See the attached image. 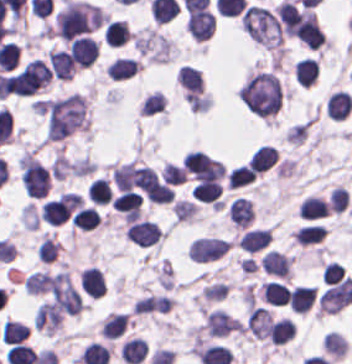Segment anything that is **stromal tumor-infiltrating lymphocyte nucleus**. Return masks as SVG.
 Wrapping results in <instances>:
<instances>
[{
    "mask_svg": "<svg viewBox=\"0 0 352 364\" xmlns=\"http://www.w3.org/2000/svg\"><path fill=\"white\" fill-rule=\"evenodd\" d=\"M182 163L186 172L197 180L219 179L224 173L223 164L198 150L184 155Z\"/></svg>",
    "mask_w": 352,
    "mask_h": 364,
    "instance_id": "1",
    "label": "stromal tumor-infiltrating lymphocyte nucleus"
},
{
    "mask_svg": "<svg viewBox=\"0 0 352 364\" xmlns=\"http://www.w3.org/2000/svg\"><path fill=\"white\" fill-rule=\"evenodd\" d=\"M229 244L223 238L197 237L187 248V255L193 262H209L218 259Z\"/></svg>",
    "mask_w": 352,
    "mask_h": 364,
    "instance_id": "2",
    "label": "stromal tumor-infiltrating lymphocyte nucleus"
},
{
    "mask_svg": "<svg viewBox=\"0 0 352 364\" xmlns=\"http://www.w3.org/2000/svg\"><path fill=\"white\" fill-rule=\"evenodd\" d=\"M124 233L130 242L141 247L152 246L162 235V231L155 221L137 218L129 224Z\"/></svg>",
    "mask_w": 352,
    "mask_h": 364,
    "instance_id": "3",
    "label": "stromal tumor-infiltrating lymphocyte nucleus"
},
{
    "mask_svg": "<svg viewBox=\"0 0 352 364\" xmlns=\"http://www.w3.org/2000/svg\"><path fill=\"white\" fill-rule=\"evenodd\" d=\"M68 49L77 67H89L98 55L96 40L83 35L71 40Z\"/></svg>",
    "mask_w": 352,
    "mask_h": 364,
    "instance_id": "4",
    "label": "stromal tumor-infiltrating lymphocyte nucleus"
},
{
    "mask_svg": "<svg viewBox=\"0 0 352 364\" xmlns=\"http://www.w3.org/2000/svg\"><path fill=\"white\" fill-rule=\"evenodd\" d=\"M185 26L191 36L204 40L211 36L214 28V14L211 10L201 9L187 16Z\"/></svg>",
    "mask_w": 352,
    "mask_h": 364,
    "instance_id": "5",
    "label": "stromal tumor-infiltrating lymphocyte nucleus"
},
{
    "mask_svg": "<svg viewBox=\"0 0 352 364\" xmlns=\"http://www.w3.org/2000/svg\"><path fill=\"white\" fill-rule=\"evenodd\" d=\"M79 281L84 293L89 296L96 299L104 295L105 278L99 267L92 264L82 269L79 274Z\"/></svg>",
    "mask_w": 352,
    "mask_h": 364,
    "instance_id": "6",
    "label": "stromal tumor-infiltrating lymphocyte nucleus"
},
{
    "mask_svg": "<svg viewBox=\"0 0 352 364\" xmlns=\"http://www.w3.org/2000/svg\"><path fill=\"white\" fill-rule=\"evenodd\" d=\"M259 261L265 274L287 277L291 259L286 254L267 249Z\"/></svg>",
    "mask_w": 352,
    "mask_h": 364,
    "instance_id": "7",
    "label": "stromal tumor-infiltrating lymphocyte nucleus"
},
{
    "mask_svg": "<svg viewBox=\"0 0 352 364\" xmlns=\"http://www.w3.org/2000/svg\"><path fill=\"white\" fill-rule=\"evenodd\" d=\"M185 97H193L203 91V80L197 68L181 66L176 77Z\"/></svg>",
    "mask_w": 352,
    "mask_h": 364,
    "instance_id": "8",
    "label": "stromal tumor-infiltrating lymphocyte nucleus"
},
{
    "mask_svg": "<svg viewBox=\"0 0 352 364\" xmlns=\"http://www.w3.org/2000/svg\"><path fill=\"white\" fill-rule=\"evenodd\" d=\"M48 67L52 76L61 79H70L75 67L64 50H49L47 52Z\"/></svg>",
    "mask_w": 352,
    "mask_h": 364,
    "instance_id": "9",
    "label": "stromal tumor-infiltrating lymphocyte nucleus"
},
{
    "mask_svg": "<svg viewBox=\"0 0 352 364\" xmlns=\"http://www.w3.org/2000/svg\"><path fill=\"white\" fill-rule=\"evenodd\" d=\"M221 192L222 186L217 179H201L194 186L191 196L200 201L220 206Z\"/></svg>",
    "mask_w": 352,
    "mask_h": 364,
    "instance_id": "10",
    "label": "stromal tumor-infiltrating lymphocyte nucleus"
},
{
    "mask_svg": "<svg viewBox=\"0 0 352 364\" xmlns=\"http://www.w3.org/2000/svg\"><path fill=\"white\" fill-rule=\"evenodd\" d=\"M316 296L312 285H298L288 292V307L293 312H305L310 309Z\"/></svg>",
    "mask_w": 352,
    "mask_h": 364,
    "instance_id": "11",
    "label": "stromal tumor-infiltrating lymphocyte nucleus"
},
{
    "mask_svg": "<svg viewBox=\"0 0 352 364\" xmlns=\"http://www.w3.org/2000/svg\"><path fill=\"white\" fill-rule=\"evenodd\" d=\"M270 240V232L268 228L254 227L248 228L238 238V246L248 252H256L265 247Z\"/></svg>",
    "mask_w": 352,
    "mask_h": 364,
    "instance_id": "12",
    "label": "stromal tumor-infiltrating lymphocyte nucleus"
},
{
    "mask_svg": "<svg viewBox=\"0 0 352 364\" xmlns=\"http://www.w3.org/2000/svg\"><path fill=\"white\" fill-rule=\"evenodd\" d=\"M147 352L145 340L131 336L120 344L119 356L127 364H138Z\"/></svg>",
    "mask_w": 352,
    "mask_h": 364,
    "instance_id": "13",
    "label": "stromal tumor-infiltrating lymphocyte nucleus"
},
{
    "mask_svg": "<svg viewBox=\"0 0 352 364\" xmlns=\"http://www.w3.org/2000/svg\"><path fill=\"white\" fill-rule=\"evenodd\" d=\"M352 107L349 93L343 90L331 92L326 104L327 115L335 120H342Z\"/></svg>",
    "mask_w": 352,
    "mask_h": 364,
    "instance_id": "14",
    "label": "stromal tumor-infiltrating lymphocyte nucleus"
},
{
    "mask_svg": "<svg viewBox=\"0 0 352 364\" xmlns=\"http://www.w3.org/2000/svg\"><path fill=\"white\" fill-rule=\"evenodd\" d=\"M130 34L126 21L113 19L107 21L102 30V38L108 45L119 46L126 42Z\"/></svg>",
    "mask_w": 352,
    "mask_h": 364,
    "instance_id": "15",
    "label": "stromal tumor-infiltrating lymphocyte nucleus"
},
{
    "mask_svg": "<svg viewBox=\"0 0 352 364\" xmlns=\"http://www.w3.org/2000/svg\"><path fill=\"white\" fill-rule=\"evenodd\" d=\"M139 66L134 59L129 57H115L105 71V76L115 80H123L134 75Z\"/></svg>",
    "mask_w": 352,
    "mask_h": 364,
    "instance_id": "16",
    "label": "stromal tumor-infiltrating lymphocyte nucleus"
},
{
    "mask_svg": "<svg viewBox=\"0 0 352 364\" xmlns=\"http://www.w3.org/2000/svg\"><path fill=\"white\" fill-rule=\"evenodd\" d=\"M276 161L275 148L269 144H262L255 148L248 158L250 170L264 171Z\"/></svg>",
    "mask_w": 352,
    "mask_h": 364,
    "instance_id": "17",
    "label": "stromal tumor-infiltrating lymphocyte nucleus"
},
{
    "mask_svg": "<svg viewBox=\"0 0 352 364\" xmlns=\"http://www.w3.org/2000/svg\"><path fill=\"white\" fill-rule=\"evenodd\" d=\"M286 296L285 285L273 279L259 285V298L269 305H282Z\"/></svg>",
    "mask_w": 352,
    "mask_h": 364,
    "instance_id": "18",
    "label": "stromal tumor-infiltrating lymphocyte nucleus"
},
{
    "mask_svg": "<svg viewBox=\"0 0 352 364\" xmlns=\"http://www.w3.org/2000/svg\"><path fill=\"white\" fill-rule=\"evenodd\" d=\"M269 334L274 345H282L291 340L295 332L287 316H280L270 321Z\"/></svg>",
    "mask_w": 352,
    "mask_h": 364,
    "instance_id": "19",
    "label": "stromal tumor-infiltrating lymphocyte nucleus"
},
{
    "mask_svg": "<svg viewBox=\"0 0 352 364\" xmlns=\"http://www.w3.org/2000/svg\"><path fill=\"white\" fill-rule=\"evenodd\" d=\"M293 71L295 81L307 87L314 82L318 67L315 61L305 56L295 61Z\"/></svg>",
    "mask_w": 352,
    "mask_h": 364,
    "instance_id": "20",
    "label": "stromal tumor-infiltrating lymphocyte nucleus"
},
{
    "mask_svg": "<svg viewBox=\"0 0 352 364\" xmlns=\"http://www.w3.org/2000/svg\"><path fill=\"white\" fill-rule=\"evenodd\" d=\"M125 326L126 318L123 313H109L100 324L99 335L111 340L123 332Z\"/></svg>",
    "mask_w": 352,
    "mask_h": 364,
    "instance_id": "21",
    "label": "stromal tumor-infiltrating lymphocyte nucleus"
},
{
    "mask_svg": "<svg viewBox=\"0 0 352 364\" xmlns=\"http://www.w3.org/2000/svg\"><path fill=\"white\" fill-rule=\"evenodd\" d=\"M299 215L301 218H317L326 216V203L325 200L313 196L306 195L298 206Z\"/></svg>",
    "mask_w": 352,
    "mask_h": 364,
    "instance_id": "22",
    "label": "stromal tumor-infiltrating lymphocyte nucleus"
},
{
    "mask_svg": "<svg viewBox=\"0 0 352 364\" xmlns=\"http://www.w3.org/2000/svg\"><path fill=\"white\" fill-rule=\"evenodd\" d=\"M324 229L320 223H312L299 227L291 236L299 246H307L322 239Z\"/></svg>",
    "mask_w": 352,
    "mask_h": 364,
    "instance_id": "23",
    "label": "stromal tumor-infiltrating lymphocyte nucleus"
},
{
    "mask_svg": "<svg viewBox=\"0 0 352 364\" xmlns=\"http://www.w3.org/2000/svg\"><path fill=\"white\" fill-rule=\"evenodd\" d=\"M26 324L12 320H5L0 328V338L2 343L13 344L22 341L27 335Z\"/></svg>",
    "mask_w": 352,
    "mask_h": 364,
    "instance_id": "24",
    "label": "stromal tumor-infiltrating lymphocyte nucleus"
},
{
    "mask_svg": "<svg viewBox=\"0 0 352 364\" xmlns=\"http://www.w3.org/2000/svg\"><path fill=\"white\" fill-rule=\"evenodd\" d=\"M99 222L100 217L98 214L90 206H83L72 216L71 225L72 227L89 231Z\"/></svg>",
    "mask_w": 352,
    "mask_h": 364,
    "instance_id": "25",
    "label": "stromal tumor-infiltrating lymphocyte nucleus"
},
{
    "mask_svg": "<svg viewBox=\"0 0 352 364\" xmlns=\"http://www.w3.org/2000/svg\"><path fill=\"white\" fill-rule=\"evenodd\" d=\"M86 193L95 205H103L110 200L111 192L103 178H95L87 187Z\"/></svg>",
    "mask_w": 352,
    "mask_h": 364,
    "instance_id": "26",
    "label": "stromal tumor-infiltrating lymphocyte nucleus"
},
{
    "mask_svg": "<svg viewBox=\"0 0 352 364\" xmlns=\"http://www.w3.org/2000/svg\"><path fill=\"white\" fill-rule=\"evenodd\" d=\"M255 179V173L247 166L240 165L227 175L228 188H237L249 184Z\"/></svg>",
    "mask_w": 352,
    "mask_h": 364,
    "instance_id": "27",
    "label": "stromal tumor-infiltrating lymphocyte nucleus"
},
{
    "mask_svg": "<svg viewBox=\"0 0 352 364\" xmlns=\"http://www.w3.org/2000/svg\"><path fill=\"white\" fill-rule=\"evenodd\" d=\"M160 179L167 184H181L186 179V171L178 165L165 161L160 168Z\"/></svg>",
    "mask_w": 352,
    "mask_h": 364,
    "instance_id": "28",
    "label": "stromal tumor-infiltrating lymphocyte nucleus"
},
{
    "mask_svg": "<svg viewBox=\"0 0 352 364\" xmlns=\"http://www.w3.org/2000/svg\"><path fill=\"white\" fill-rule=\"evenodd\" d=\"M58 248L59 245L55 240L45 233L36 249V255L45 263H52L58 252Z\"/></svg>",
    "mask_w": 352,
    "mask_h": 364,
    "instance_id": "29",
    "label": "stromal tumor-infiltrating lymphocyte nucleus"
},
{
    "mask_svg": "<svg viewBox=\"0 0 352 364\" xmlns=\"http://www.w3.org/2000/svg\"><path fill=\"white\" fill-rule=\"evenodd\" d=\"M165 102V97L161 91H153L146 97H144L140 107L139 112L144 114H152L158 112L161 106Z\"/></svg>",
    "mask_w": 352,
    "mask_h": 364,
    "instance_id": "30",
    "label": "stromal tumor-infiltrating lymphocyte nucleus"
},
{
    "mask_svg": "<svg viewBox=\"0 0 352 364\" xmlns=\"http://www.w3.org/2000/svg\"><path fill=\"white\" fill-rule=\"evenodd\" d=\"M197 212V206L194 202H189L185 200H177L171 205V213L175 221H182L192 214Z\"/></svg>",
    "mask_w": 352,
    "mask_h": 364,
    "instance_id": "31",
    "label": "stromal tumor-infiltrating lymphocyte nucleus"
},
{
    "mask_svg": "<svg viewBox=\"0 0 352 364\" xmlns=\"http://www.w3.org/2000/svg\"><path fill=\"white\" fill-rule=\"evenodd\" d=\"M343 274H344L343 266L339 264L337 261H330L327 264H325L321 278L322 281L328 285L342 278Z\"/></svg>",
    "mask_w": 352,
    "mask_h": 364,
    "instance_id": "32",
    "label": "stromal tumor-infiltrating lymphocyte nucleus"
}]
</instances>
